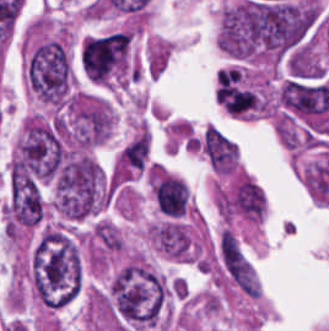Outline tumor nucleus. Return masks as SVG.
Returning a JSON list of instances; mask_svg holds the SVG:
<instances>
[{"label":"tumor nucleus","instance_id":"3d1891a8","mask_svg":"<svg viewBox=\"0 0 329 331\" xmlns=\"http://www.w3.org/2000/svg\"><path fill=\"white\" fill-rule=\"evenodd\" d=\"M199 149L212 168L221 174H232L238 164L234 142L215 125H207L199 139Z\"/></svg>","mask_w":329,"mask_h":331},{"label":"tumor nucleus","instance_id":"5ab6c2c4","mask_svg":"<svg viewBox=\"0 0 329 331\" xmlns=\"http://www.w3.org/2000/svg\"><path fill=\"white\" fill-rule=\"evenodd\" d=\"M81 72L96 82H122L134 76L130 31L117 29L84 39L78 54Z\"/></svg>","mask_w":329,"mask_h":331},{"label":"tumor nucleus","instance_id":"2f306a5c","mask_svg":"<svg viewBox=\"0 0 329 331\" xmlns=\"http://www.w3.org/2000/svg\"><path fill=\"white\" fill-rule=\"evenodd\" d=\"M29 276L43 304H66L82 282V264L72 236L59 227H45L29 259Z\"/></svg>","mask_w":329,"mask_h":331},{"label":"tumor nucleus","instance_id":"8643909e","mask_svg":"<svg viewBox=\"0 0 329 331\" xmlns=\"http://www.w3.org/2000/svg\"><path fill=\"white\" fill-rule=\"evenodd\" d=\"M168 290L164 280L142 259L130 258L112 277L108 299L113 312L128 328L157 324Z\"/></svg>","mask_w":329,"mask_h":331},{"label":"tumor nucleus","instance_id":"2cbd58db","mask_svg":"<svg viewBox=\"0 0 329 331\" xmlns=\"http://www.w3.org/2000/svg\"><path fill=\"white\" fill-rule=\"evenodd\" d=\"M111 116L102 100L72 94L58 110L54 122L62 139L71 147L87 148L108 135Z\"/></svg>","mask_w":329,"mask_h":331}]
</instances>
